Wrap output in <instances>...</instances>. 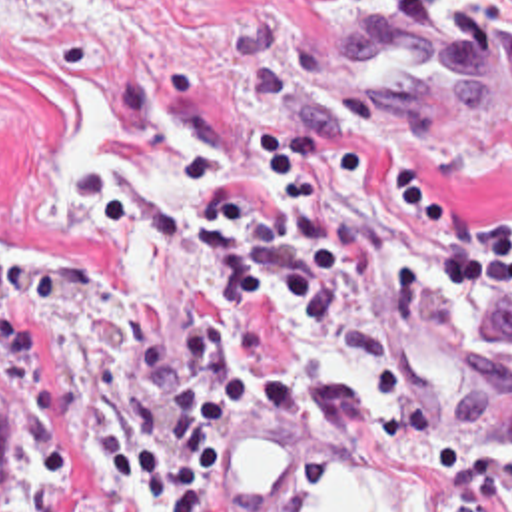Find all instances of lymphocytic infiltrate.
Returning <instances> with one entry per match:
<instances>
[{"label":"lymphocytic infiltrate","mask_w":512,"mask_h":512,"mask_svg":"<svg viewBox=\"0 0 512 512\" xmlns=\"http://www.w3.org/2000/svg\"><path fill=\"white\" fill-rule=\"evenodd\" d=\"M265 193L207 153H179L177 173L201 209L159 211V243L207 261L217 307H277L317 331L348 315L360 293L372 331L402 337L416 327L422 283L414 253L372 267V241L340 189H366L380 235L428 253L438 287H484L512 299V219L472 221L428 195L420 167L384 163L362 137H328L311 125L253 131ZM137 369L169 398L159 444L97 398L91 428L125 486L163 512H223V450L241 420L265 424L301 406L295 375L277 359L243 353L235 315H187L173 355L135 333ZM376 438L430 466L442 512H512V452L482 482L450 432L424 408L392 402L370 410Z\"/></svg>","instance_id":"1"}]
</instances>
